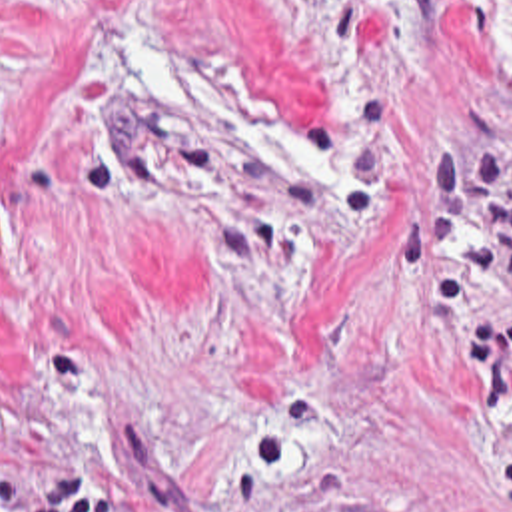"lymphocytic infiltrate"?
Wrapping results in <instances>:
<instances>
[{
	"instance_id": "obj_1",
	"label": "lymphocytic infiltrate",
	"mask_w": 512,
	"mask_h": 512,
	"mask_svg": "<svg viewBox=\"0 0 512 512\" xmlns=\"http://www.w3.org/2000/svg\"><path fill=\"white\" fill-rule=\"evenodd\" d=\"M0 512H127L106 492L94 490L80 472H54L34 498H22L14 480L0 476Z\"/></svg>"
}]
</instances>
